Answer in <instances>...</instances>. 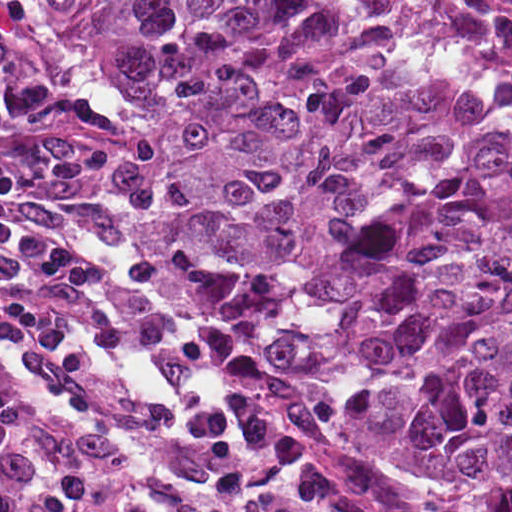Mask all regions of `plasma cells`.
I'll list each match as a JSON object with an SVG mask.
<instances>
[{
	"label": "plasma cells",
	"instance_id": "plasma-cells-1",
	"mask_svg": "<svg viewBox=\"0 0 512 512\" xmlns=\"http://www.w3.org/2000/svg\"><path fill=\"white\" fill-rule=\"evenodd\" d=\"M161 152L135 129L0 186V512H430L311 459L254 361L151 306Z\"/></svg>",
	"mask_w": 512,
	"mask_h": 512
}]
</instances>
